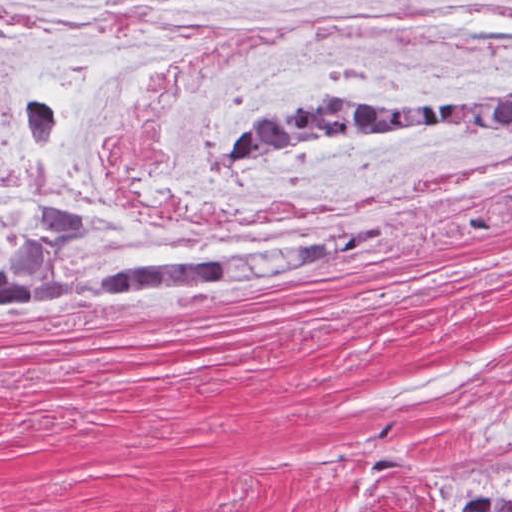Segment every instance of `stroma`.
I'll return each instance as SVG.
<instances>
[{
  "instance_id": "1",
  "label": "stroma",
  "mask_w": 512,
  "mask_h": 512,
  "mask_svg": "<svg viewBox=\"0 0 512 512\" xmlns=\"http://www.w3.org/2000/svg\"><path fill=\"white\" fill-rule=\"evenodd\" d=\"M0 512H512V211L283 278L0 303Z\"/></svg>"
}]
</instances>
